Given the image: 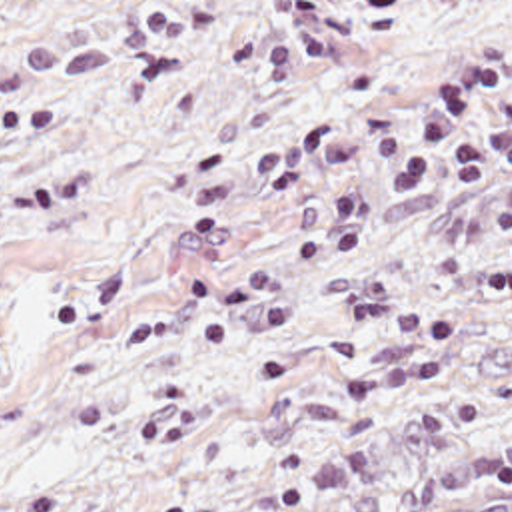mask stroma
I'll return each instance as SVG.
<instances>
[{
	"label": "stroma",
	"instance_id": "35a3bbf8",
	"mask_svg": "<svg viewBox=\"0 0 512 512\" xmlns=\"http://www.w3.org/2000/svg\"><path fill=\"white\" fill-rule=\"evenodd\" d=\"M510 425L512 0H0V512Z\"/></svg>",
	"mask_w": 512,
	"mask_h": 512
}]
</instances>
